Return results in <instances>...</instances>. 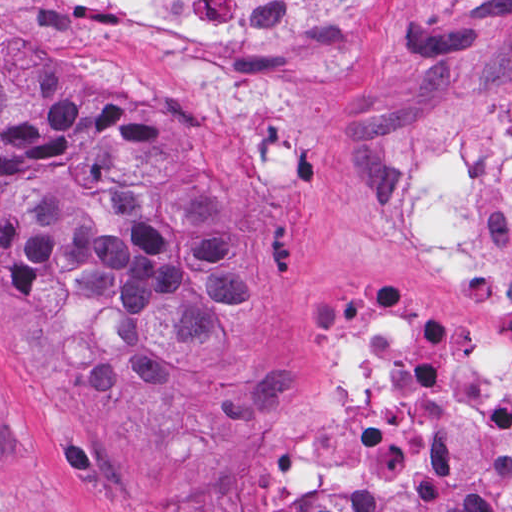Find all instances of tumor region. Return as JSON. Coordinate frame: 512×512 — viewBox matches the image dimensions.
Here are the masks:
<instances>
[{
	"label": "tumor region",
	"instance_id": "tumor-region-1",
	"mask_svg": "<svg viewBox=\"0 0 512 512\" xmlns=\"http://www.w3.org/2000/svg\"><path fill=\"white\" fill-rule=\"evenodd\" d=\"M265 292L242 198L217 170L87 92L65 60L0 57V335L48 400L192 408L233 373ZM254 512L434 511L316 491Z\"/></svg>",
	"mask_w": 512,
	"mask_h": 512
}]
</instances>
